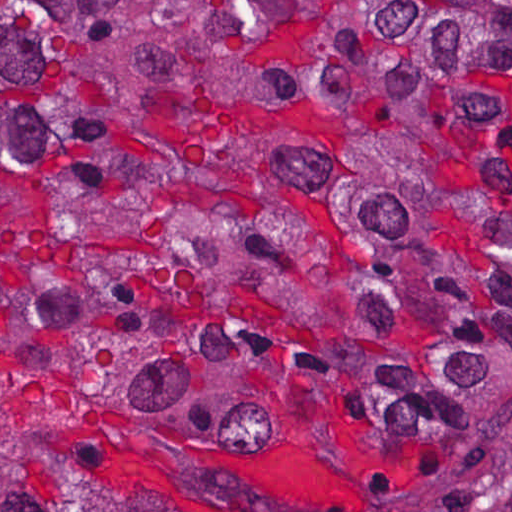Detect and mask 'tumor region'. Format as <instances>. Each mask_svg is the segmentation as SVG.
Returning a JSON list of instances; mask_svg holds the SVG:
<instances>
[{
	"label": "tumor region",
	"mask_w": 512,
	"mask_h": 512,
	"mask_svg": "<svg viewBox=\"0 0 512 512\" xmlns=\"http://www.w3.org/2000/svg\"><path fill=\"white\" fill-rule=\"evenodd\" d=\"M512 512V0H0V512Z\"/></svg>",
	"instance_id": "1"
}]
</instances>
